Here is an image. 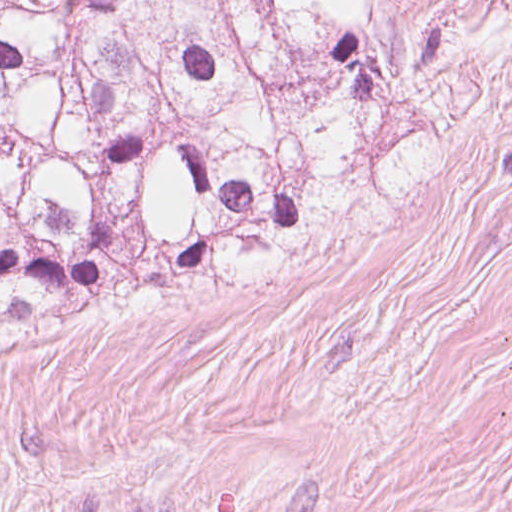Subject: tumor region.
<instances>
[{
	"instance_id": "e687c5a6",
	"label": "tumor region",
	"mask_w": 512,
	"mask_h": 512,
	"mask_svg": "<svg viewBox=\"0 0 512 512\" xmlns=\"http://www.w3.org/2000/svg\"><path fill=\"white\" fill-rule=\"evenodd\" d=\"M390 0H0V334L321 247L451 153L464 40Z\"/></svg>"
}]
</instances>
